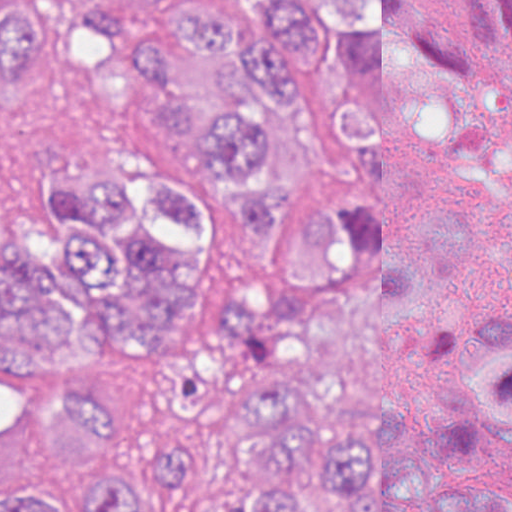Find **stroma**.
<instances>
[{
	"instance_id": "35a3bbf8",
	"label": "stroma",
	"mask_w": 512,
	"mask_h": 512,
	"mask_svg": "<svg viewBox=\"0 0 512 512\" xmlns=\"http://www.w3.org/2000/svg\"><path fill=\"white\" fill-rule=\"evenodd\" d=\"M460 0H414L477 94L469 129L440 177L443 207L464 213L472 266L496 221L512 206V45L477 47L459 21Z\"/></svg>"
}]
</instances>
